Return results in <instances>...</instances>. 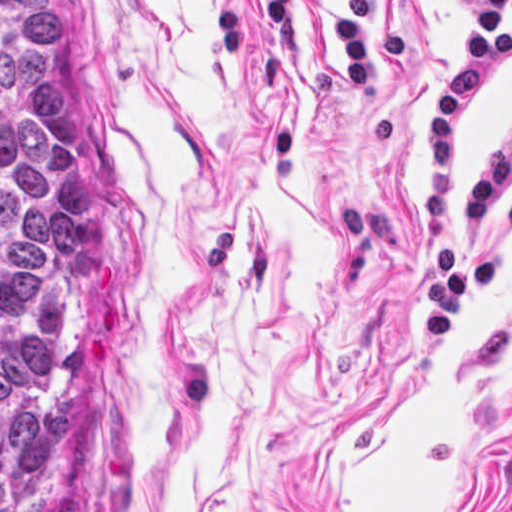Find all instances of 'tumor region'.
<instances>
[{
	"instance_id": "obj_1",
	"label": "tumor region",
	"mask_w": 512,
	"mask_h": 512,
	"mask_svg": "<svg viewBox=\"0 0 512 512\" xmlns=\"http://www.w3.org/2000/svg\"><path fill=\"white\" fill-rule=\"evenodd\" d=\"M96 163L41 0H0V512H46L80 406Z\"/></svg>"
}]
</instances>
